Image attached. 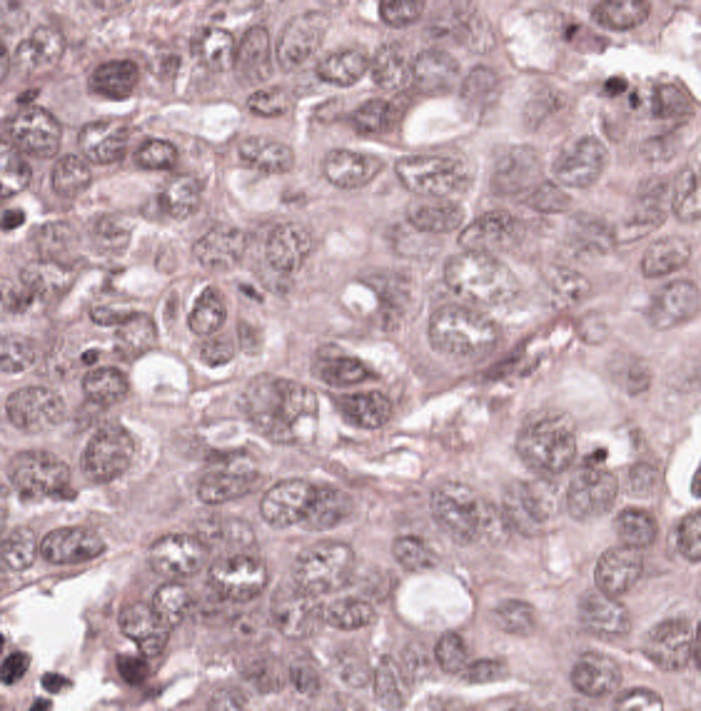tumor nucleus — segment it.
Returning a JSON list of instances; mask_svg holds the SVG:
<instances>
[{
  "label": "tumor nucleus",
  "mask_w": 701,
  "mask_h": 711,
  "mask_svg": "<svg viewBox=\"0 0 701 711\" xmlns=\"http://www.w3.org/2000/svg\"><path fill=\"white\" fill-rule=\"evenodd\" d=\"M144 63L132 51H106L88 56L81 63L83 92L108 102H122L131 95Z\"/></svg>",
  "instance_id": "tumor-nucleus-1"
}]
</instances>
